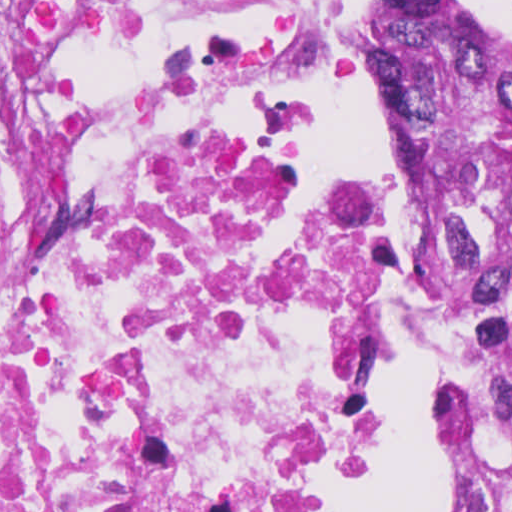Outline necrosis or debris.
Segmentation results:
<instances>
[{
  "label": "necrosis or debris",
  "mask_w": 512,
  "mask_h": 512,
  "mask_svg": "<svg viewBox=\"0 0 512 512\" xmlns=\"http://www.w3.org/2000/svg\"><path fill=\"white\" fill-rule=\"evenodd\" d=\"M338 0H0V512H354L377 216L302 178Z\"/></svg>",
  "instance_id": "4bbe7bcc"
}]
</instances>
